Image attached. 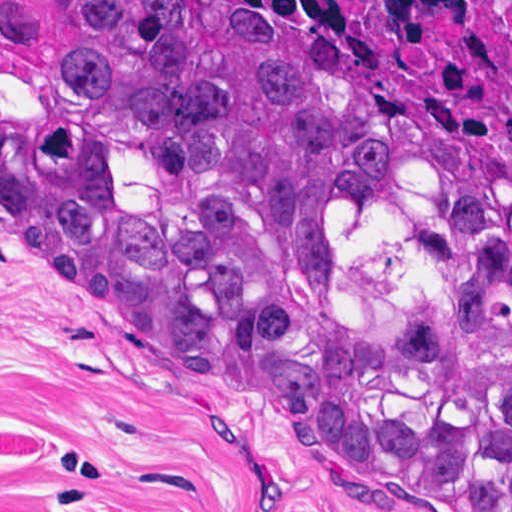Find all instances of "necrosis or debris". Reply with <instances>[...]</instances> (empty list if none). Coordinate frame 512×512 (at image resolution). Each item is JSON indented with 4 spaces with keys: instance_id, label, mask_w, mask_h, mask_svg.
I'll return each instance as SVG.
<instances>
[{
    "instance_id": "4bbe7bcc",
    "label": "necrosis or debris",
    "mask_w": 512,
    "mask_h": 512,
    "mask_svg": "<svg viewBox=\"0 0 512 512\" xmlns=\"http://www.w3.org/2000/svg\"><path fill=\"white\" fill-rule=\"evenodd\" d=\"M297 10L512 168V0H247Z\"/></svg>"
}]
</instances>
